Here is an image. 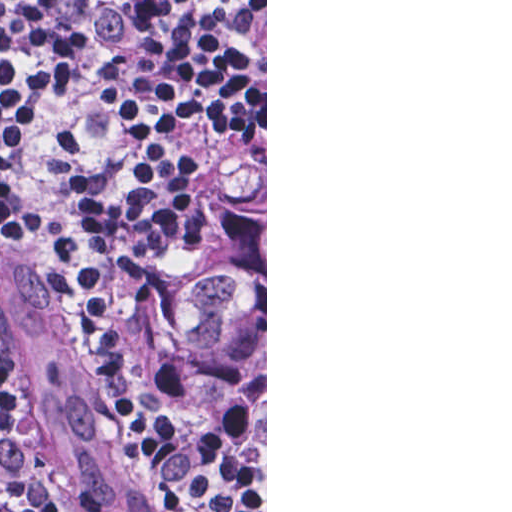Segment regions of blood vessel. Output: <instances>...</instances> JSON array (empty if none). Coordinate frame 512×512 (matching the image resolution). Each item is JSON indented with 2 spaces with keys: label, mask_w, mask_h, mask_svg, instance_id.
<instances>
[{
  "label": "blood vessel",
  "mask_w": 512,
  "mask_h": 512,
  "mask_svg": "<svg viewBox=\"0 0 512 512\" xmlns=\"http://www.w3.org/2000/svg\"><path fill=\"white\" fill-rule=\"evenodd\" d=\"M18 242L0 243V366L27 407L57 512H158L54 267Z\"/></svg>",
  "instance_id": "obj_1"
}]
</instances>
